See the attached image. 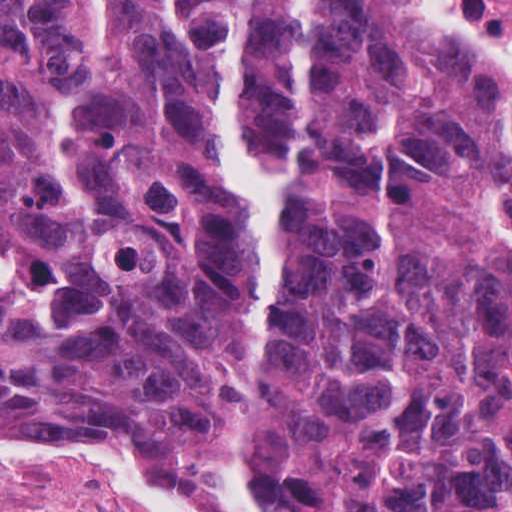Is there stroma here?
Segmentation results:
<instances>
[{"mask_svg":"<svg viewBox=\"0 0 512 512\" xmlns=\"http://www.w3.org/2000/svg\"><path fill=\"white\" fill-rule=\"evenodd\" d=\"M469 1L490 18L484 0ZM439 43L453 58L487 70L512 97V68ZM0 440H76L131 451L186 482L222 512H262L219 464L154 441L120 417L51 415L0 431ZM0 512L142 511L92 476L0 468Z\"/></svg>","mask_w":512,"mask_h":512,"instance_id":"1","label":"stroma"}]
</instances>
